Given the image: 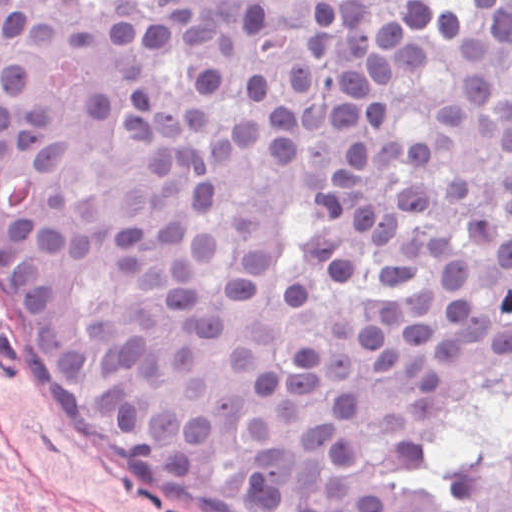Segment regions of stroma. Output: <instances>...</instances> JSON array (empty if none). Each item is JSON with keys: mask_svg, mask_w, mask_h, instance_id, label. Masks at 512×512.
I'll list each match as a JSON object with an SVG mask.
<instances>
[{"mask_svg": "<svg viewBox=\"0 0 512 512\" xmlns=\"http://www.w3.org/2000/svg\"><path fill=\"white\" fill-rule=\"evenodd\" d=\"M0 512H171L48 403L1 329Z\"/></svg>", "mask_w": 512, "mask_h": 512, "instance_id": "obj_1", "label": "stroma"}]
</instances>
